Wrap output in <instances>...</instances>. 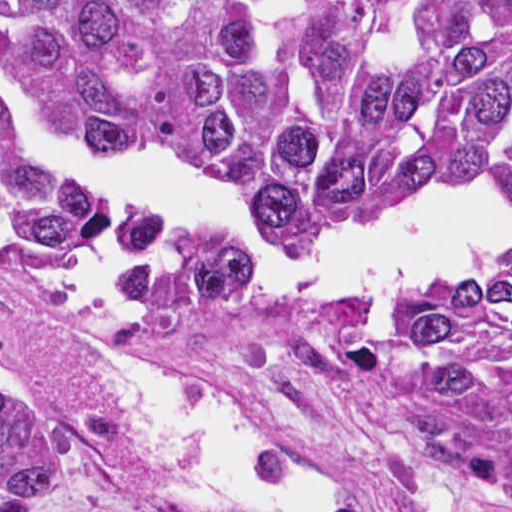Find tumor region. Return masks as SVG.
<instances>
[{
	"label": "tumor region",
	"mask_w": 512,
	"mask_h": 512,
	"mask_svg": "<svg viewBox=\"0 0 512 512\" xmlns=\"http://www.w3.org/2000/svg\"><path fill=\"white\" fill-rule=\"evenodd\" d=\"M0 71L93 148L179 153L242 187L300 250L347 256L439 183L512 202V0H0ZM104 220L0 114V239L47 263L93 251ZM169 243V283L131 320L201 363L335 358L429 453L435 512H512V260L369 319L273 296L210 228ZM72 478L0 395V512L61 503Z\"/></svg>",
	"instance_id": "e687c5a6"
}]
</instances>
